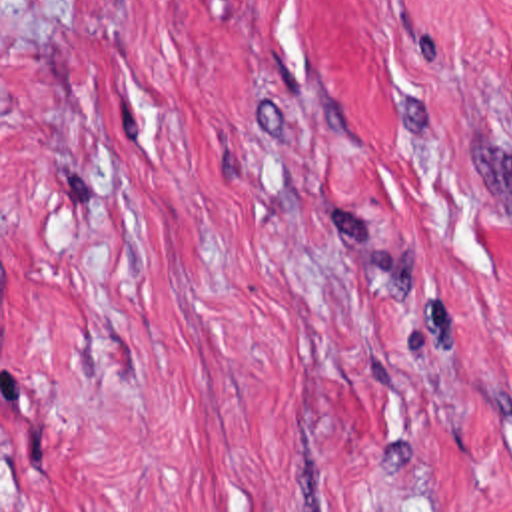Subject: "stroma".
Returning a JSON list of instances; mask_svg holds the SVG:
<instances>
[{
  "label": "stroma",
  "mask_w": 512,
  "mask_h": 512,
  "mask_svg": "<svg viewBox=\"0 0 512 512\" xmlns=\"http://www.w3.org/2000/svg\"><path fill=\"white\" fill-rule=\"evenodd\" d=\"M0 512H512V0H0Z\"/></svg>",
  "instance_id": "obj_1"
}]
</instances>
